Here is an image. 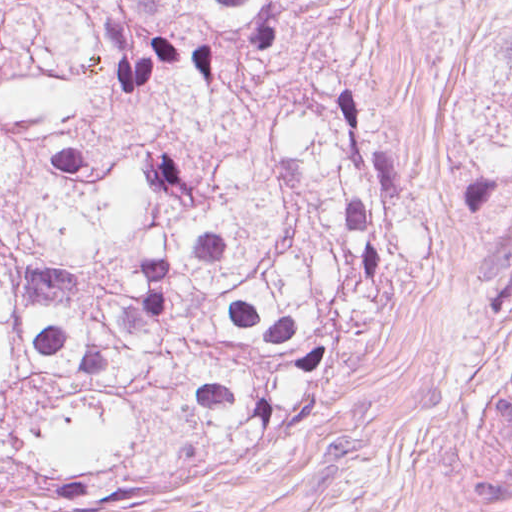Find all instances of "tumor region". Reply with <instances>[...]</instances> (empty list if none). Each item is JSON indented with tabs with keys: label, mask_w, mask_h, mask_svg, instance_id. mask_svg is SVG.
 <instances>
[{
	"label": "tumor region",
	"mask_w": 512,
	"mask_h": 512,
	"mask_svg": "<svg viewBox=\"0 0 512 512\" xmlns=\"http://www.w3.org/2000/svg\"><path fill=\"white\" fill-rule=\"evenodd\" d=\"M446 1L0 0V512L321 411L419 225L363 72Z\"/></svg>",
	"instance_id": "e687c5a6"
}]
</instances>
